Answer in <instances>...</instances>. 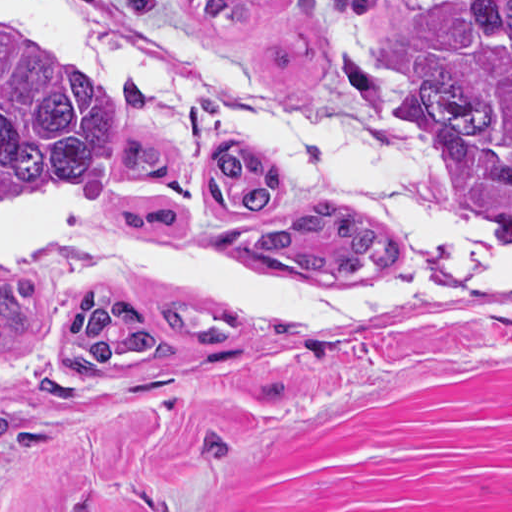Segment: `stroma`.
Instances as JSON below:
<instances>
[{"mask_svg":"<svg viewBox=\"0 0 512 512\" xmlns=\"http://www.w3.org/2000/svg\"><path fill=\"white\" fill-rule=\"evenodd\" d=\"M77 1L218 49L286 113L361 148L425 139L404 75L438 0H375L361 12L260 0L232 28L206 24L193 0H159L151 18L135 17L130 0ZM348 58L386 79L382 114L341 69ZM110 89L120 122L161 130ZM22 223L0 229V245ZM401 234L415 249L401 283L418 282L431 256ZM202 263L278 287L348 285ZM10 274L35 281L37 312L30 337L0 340L5 415L24 429L0 452V512H512V306L427 297L294 312L241 323L228 344H188L165 306L125 300L169 354L75 378L64 358L71 314L93 292L28 271L0 278Z\"/></svg>","mask_w":512,"mask_h":512,"instance_id":"obj_1","label":"stroma"}]
</instances>
